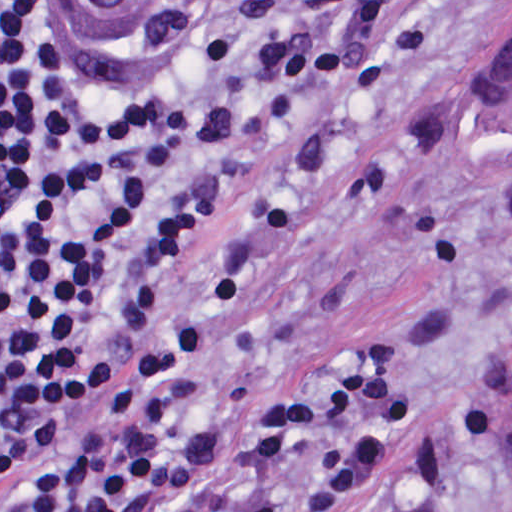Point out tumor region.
Listing matches in <instances>:
<instances>
[{"label": "tumor region", "instance_id": "obj_1", "mask_svg": "<svg viewBox=\"0 0 512 512\" xmlns=\"http://www.w3.org/2000/svg\"><path fill=\"white\" fill-rule=\"evenodd\" d=\"M460 121L480 163L512 184V39L466 90ZM492 455L495 464L512 468V431Z\"/></svg>", "mask_w": 512, "mask_h": 512}]
</instances>
